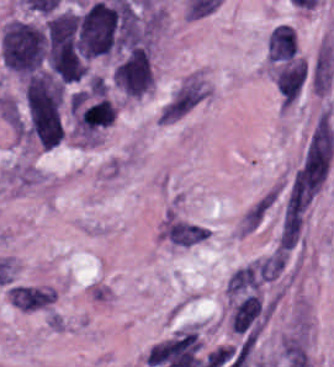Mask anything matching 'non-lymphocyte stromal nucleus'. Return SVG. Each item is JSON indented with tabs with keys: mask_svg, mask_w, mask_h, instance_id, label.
Wrapping results in <instances>:
<instances>
[{
	"mask_svg": "<svg viewBox=\"0 0 334 367\" xmlns=\"http://www.w3.org/2000/svg\"><path fill=\"white\" fill-rule=\"evenodd\" d=\"M212 86L207 72L195 68L182 76L163 101L157 124L170 125L211 98Z\"/></svg>",
	"mask_w": 334,
	"mask_h": 367,
	"instance_id": "obj_1",
	"label": "non-lymphocyte stromal nucleus"
},
{
	"mask_svg": "<svg viewBox=\"0 0 334 367\" xmlns=\"http://www.w3.org/2000/svg\"><path fill=\"white\" fill-rule=\"evenodd\" d=\"M333 158L334 126L325 108L315 119L302 154V165L305 171H329Z\"/></svg>",
	"mask_w": 334,
	"mask_h": 367,
	"instance_id": "obj_2",
	"label": "non-lymphocyte stromal nucleus"
},
{
	"mask_svg": "<svg viewBox=\"0 0 334 367\" xmlns=\"http://www.w3.org/2000/svg\"><path fill=\"white\" fill-rule=\"evenodd\" d=\"M279 194L280 186L274 183L244 207L233 227L237 239L247 237L259 229L273 209Z\"/></svg>",
	"mask_w": 334,
	"mask_h": 367,
	"instance_id": "obj_3",
	"label": "non-lymphocyte stromal nucleus"
},
{
	"mask_svg": "<svg viewBox=\"0 0 334 367\" xmlns=\"http://www.w3.org/2000/svg\"><path fill=\"white\" fill-rule=\"evenodd\" d=\"M334 75V54L332 45L322 41L310 65L309 76L315 94H326Z\"/></svg>",
	"mask_w": 334,
	"mask_h": 367,
	"instance_id": "obj_4",
	"label": "non-lymphocyte stromal nucleus"
},
{
	"mask_svg": "<svg viewBox=\"0 0 334 367\" xmlns=\"http://www.w3.org/2000/svg\"><path fill=\"white\" fill-rule=\"evenodd\" d=\"M261 300L249 294L237 302L231 311V330L237 334H258L260 327Z\"/></svg>",
	"mask_w": 334,
	"mask_h": 367,
	"instance_id": "obj_5",
	"label": "non-lymphocyte stromal nucleus"
},
{
	"mask_svg": "<svg viewBox=\"0 0 334 367\" xmlns=\"http://www.w3.org/2000/svg\"><path fill=\"white\" fill-rule=\"evenodd\" d=\"M160 233L164 241L175 247H192L207 237L202 227L176 217H169Z\"/></svg>",
	"mask_w": 334,
	"mask_h": 367,
	"instance_id": "obj_6",
	"label": "non-lymphocyte stromal nucleus"
},
{
	"mask_svg": "<svg viewBox=\"0 0 334 367\" xmlns=\"http://www.w3.org/2000/svg\"><path fill=\"white\" fill-rule=\"evenodd\" d=\"M11 305L22 311H31L49 305L55 298V292L48 288L12 286L7 289Z\"/></svg>",
	"mask_w": 334,
	"mask_h": 367,
	"instance_id": "obj_7",
	"label": "non-lymphocyte stromal nucleus"
}]
</instances>
